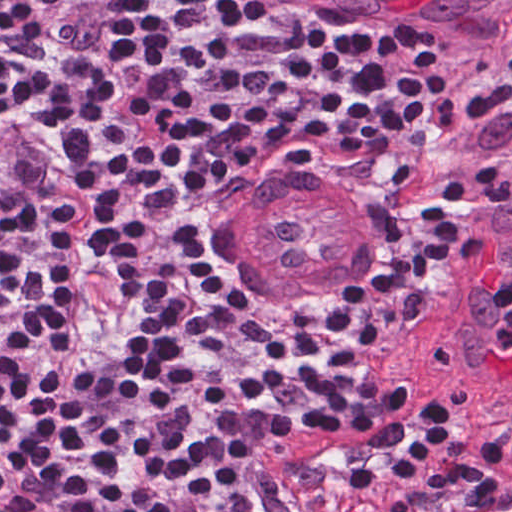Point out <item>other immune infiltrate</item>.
<instances>
[{"label":"other immune infiltrate","instance_id":"obj_1","mask_svg":"<svg viewBox=\"0 0 512 512\" xmlns=\"http://www.w3.org/2000/svg\"><path fill=\"white\" fill-rule=\"evenodd\" d=\"M506 279L493 294L497 299L500 315V325L494 335V342L502 350H512V290L504 284Z\"/></svg>","mask_w":512,"mask_h":512}]
</instances>
